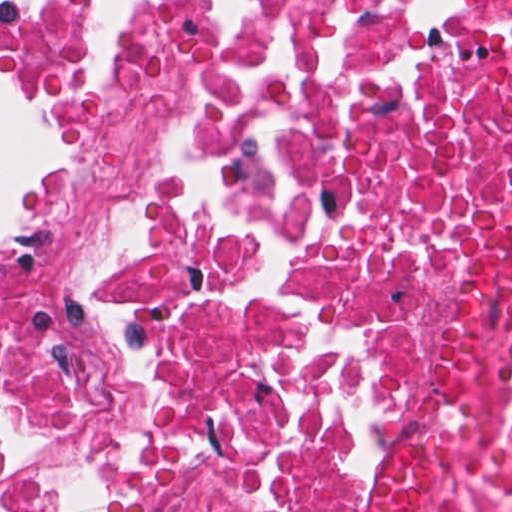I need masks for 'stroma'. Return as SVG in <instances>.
I'll return each instance as SVG.
<instances>
[{"label": "stroma", "mask_w": 512, "mask_h": 512, "mask_svg": "<svg viewBox=\"0 0 512 512\" xmlns=\"http://www.w3.org/2000/svg\"><path fill=\"white\" fill-rule=\"evenodd\" d=\"M129 1L134 0H52L44 8H1L0 106L4 111L0 114L32 126L49 142L19 92L16 75L19 32L41 19H61L86 14ZM77 164L78 159L64 158L59 173L15 181L3 203L0 245L70 190ZM0 405L36 430L24 451H0V483H3L23 476L26 460L37 437L41 416L1 376Z\"/></svg>", "instance_id": "35a3bbf8"}]
</instances>
